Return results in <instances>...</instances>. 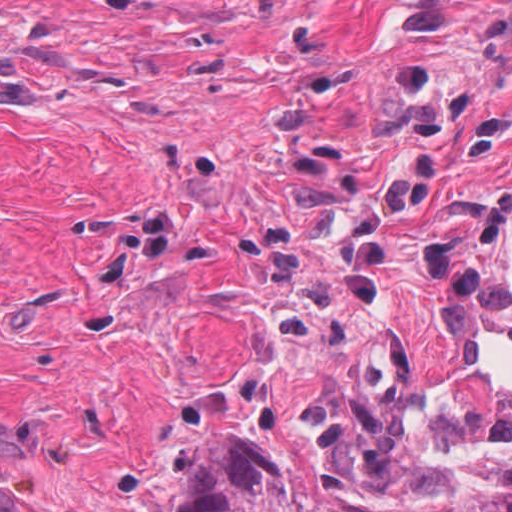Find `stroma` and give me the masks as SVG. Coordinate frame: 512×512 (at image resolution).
Wrapping results in <instances>:
<instances>
[{
  "instance_id": "obj_1",
  "label": "stroma",
  "mask_w": 512,
  "mask_h": 512,
  "mask_svg": "<svg viewBox=\"0 0 512 512\" xmlns=\"http://www.w3.org/2000/svg\"><path fill=\"white\" fill-rule=\"evenodd\" d=\"M439 388H512V241L231 403L236 432L371 502L512 479V453H427ZM177 435L44 512H175Z\"/></svg>"
}]
</instances>
